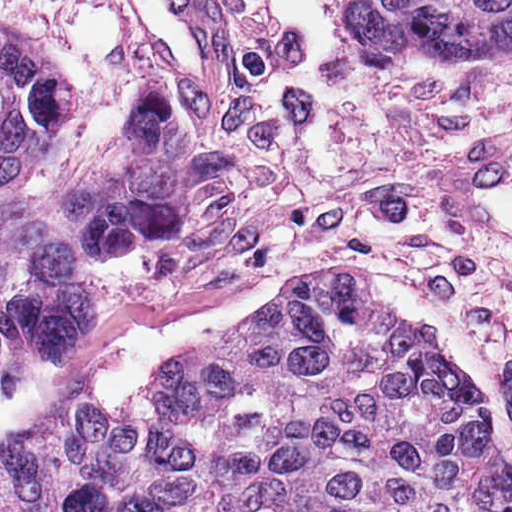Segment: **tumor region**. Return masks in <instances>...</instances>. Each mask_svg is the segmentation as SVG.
I'll use <instances>...</instances> for the list:
<instances>
[{"instance_id": "obj_1", "label": "tumor region", "mask_w": 512, "mask_h": 512, "mask_svg": "<svg viewBox=\"0 0 512 512\" xmlns=\"http://www.w3.org/2000/svg\"><path fill=\"white\" fill-rule=\"evenodd\" d=\"M370 58L467 63L512 46V0H352ZM71 112L59 52L0 11V396L32 340L90 332L89 259L134 253L191 212L189 121L145 80L110 138L58 189L17 195ZM360 268L172 359L127 402L69 396L0 454V512H512V462L484 398Z\"/></svg>"}]
</instances>
